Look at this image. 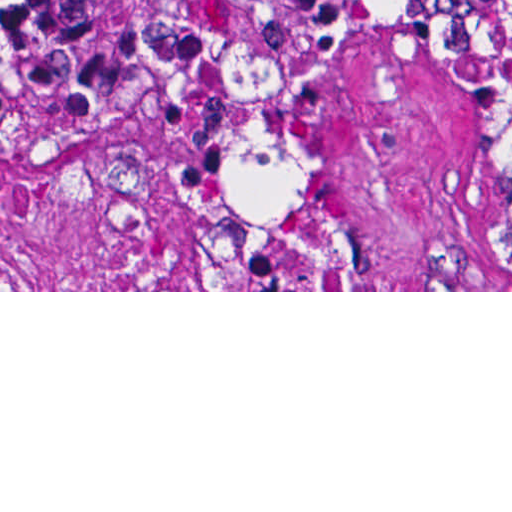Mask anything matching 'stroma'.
Segmentation results:
<instances>
[{"label": "stroma", "instance_id": "1", "mask_svg": "<svg viewBox=\"0 0 512 512\" xmlns=\"http://www.w3.org/2000/svg\"><path fill=\"white\" fill-rule=\"evenodd\" d=\"M512 0H445L324 44L214 58L148 113H57L0 75V292H512V224L463 43ZM260 93L347 221L349 290H212L210 121Z\"/></svg>", "mask_w": 512, "mask_h": 512}]
</instances>
